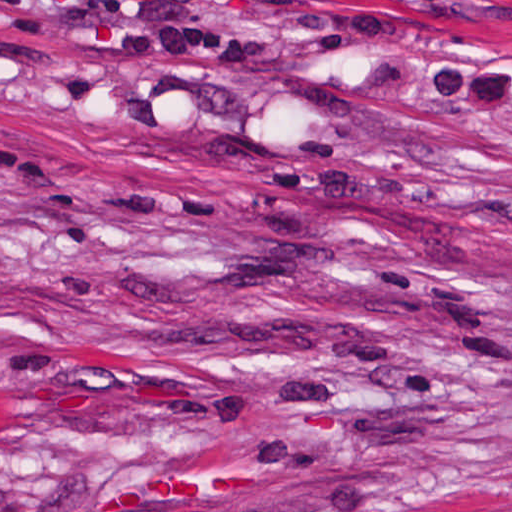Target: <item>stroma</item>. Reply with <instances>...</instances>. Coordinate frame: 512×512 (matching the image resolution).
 <instances>
[{"mask_svg":"<svg viewBox=\"0 0 512 512\" xmlns=\"http://www.w3.org/2000/svg\"><path fill=\"white\" fill-rule=\"evenodd\" d=\"M0 485L512 490V0H0Z\"/></svg>","mask_w":512,"mask_h":512,"instance_id":"obj_1","label":"stroma"}]
</instances>
